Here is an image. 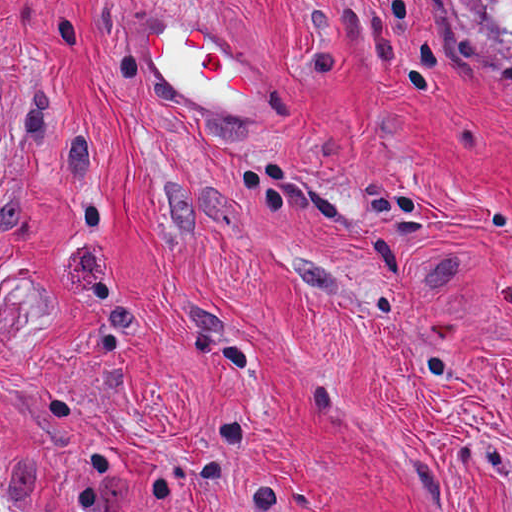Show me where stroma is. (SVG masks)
<instances>
[{
  "label": "stroma",
  "instance_id": "35a3bbf8",
  "mask_svg": "<svg viewBox=\"0 0 512 512\" xmlns=\"http://www.w3.org/2000/svg\"><path fill=\"white\" fill-rule=\"evenodd\" d=\"M260 67L173 97L149 24ZM0 512H512V59L436 0H0Z\"/></svg>",
  "mask_w": 512,
  "mask_h": 512
}]
</instances>
